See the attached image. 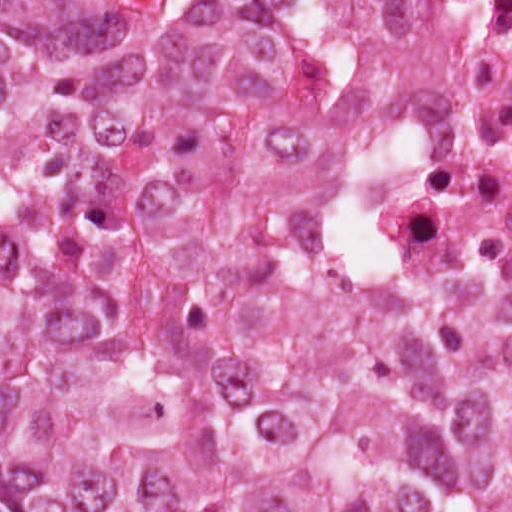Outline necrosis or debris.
Returning a JSON list of instances; mask_svg holds the SVG:
<instances>
[{"instance_id": "necrosis-or-debris-1", "label": "necrosis or debris", "mask_w": 512, "mask_h": 512, "mask_svg": "<svg viewBox=\"0 0 512 512\" xmlns=\"http://www.w3.org/2000/svg\"><path fill=\"white\" fill-rule=\"evenodd\" d=\"M421 16L459 127L399 195L390 229L458 276H511L512 0H421Z\"/></svg>"}]
</instances>
